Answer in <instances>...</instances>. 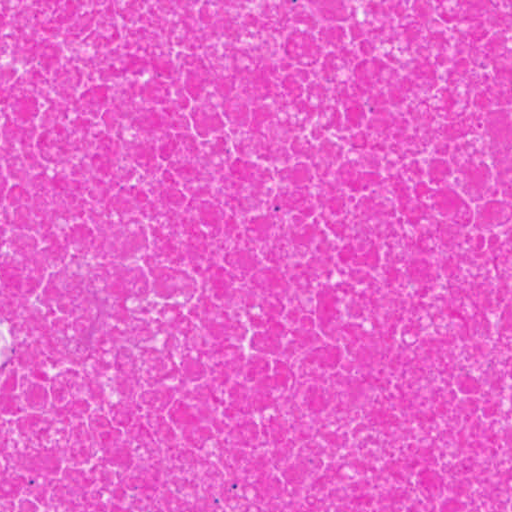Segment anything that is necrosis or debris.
Here are the masks:
<instances>
[{
	"label": "necrosis or debris",
	"instance_id": "1",
	"mask_svg": "<svg viewBox=\"0 0 512 512\" xmlns=\"http://www.w3.org/2000/svg\"><path fill=\"white\" fill-rule=\"evenodd\" d=\"M0 512H512V1H0Z\"/></svg>",
	"mask_w": 512,
	"mask_h": 512
}]
</instances>
